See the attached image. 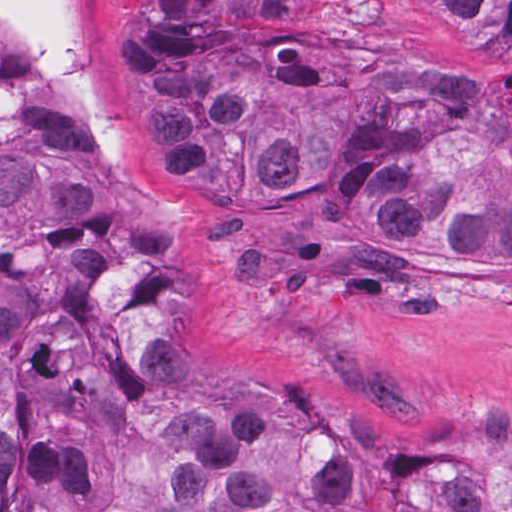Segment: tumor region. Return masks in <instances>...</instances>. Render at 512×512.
Listing matches in <instances>:
<instances>
[{
    "label": "tumor region",
    "mask_w": 512,
    "mask_h": 512,
    "mask_svg": "<svg viewBox=\"0 0 512 512\" xmlns=\"http://www.w3.org/2000/svg\"><path fill=\"white\" fill-rule=\"evenodd\" d=\"M167 154L215 214L360 286L512 271V0H119ZM181 230L78 98L0 50V512H512L379 477L200 370Z\"/></svg>",
    "instance_id": "tumor-region-1"
}]
</instances>
